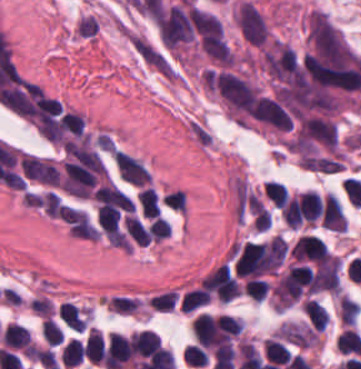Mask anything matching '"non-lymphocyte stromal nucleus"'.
I'll list each match as a JSON object with an SVG mask.
<instances>
[{"label":"non-lymphocyte stromal nucleus","mask_w":361,"mask_h":369,"mask_svg":"<svg viewBox=\"0 0 361 369\" xmlns=\"http://www.w3.org/2000/svg\"><path fill=\"white\" fill-rule=\"evenodd\" d=\"M186 132L192 142L206 152L214 147L216 137L206 119L188 116L186 119Z\"/></svg>","instance_id":"non-lymphocyte-stromal-nucleus-1"}]
</instances>
